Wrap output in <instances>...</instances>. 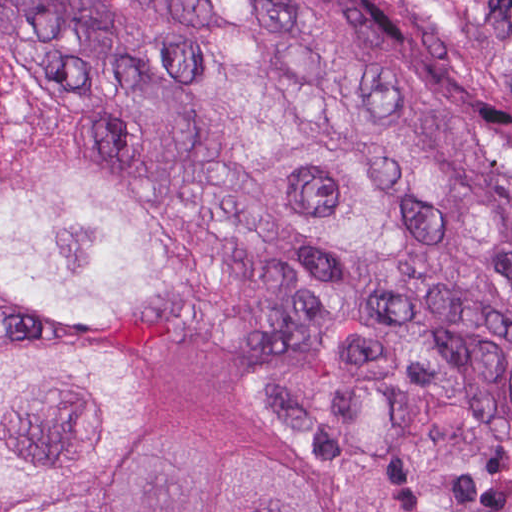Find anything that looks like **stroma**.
<instances>
[{"label": "stroma", "mask_w": 512, "mask_h": 512, "mask_svg": "<svg viewBox=\"0 0 512 512\" xmlns=\"http://www.w3.org/2000/svg\"><path fill=\"white\" fill-rule=\"evenodd\" d=\"M0 334H43L129 367L168 427L223 442L235 457L284 465L317 485L334 512H343L334 464L279 393L224 350H175L114 318L36 322L15 310H0Z\"/></svg>", "instance_id": "35a3bbf8"}]
</instances>
